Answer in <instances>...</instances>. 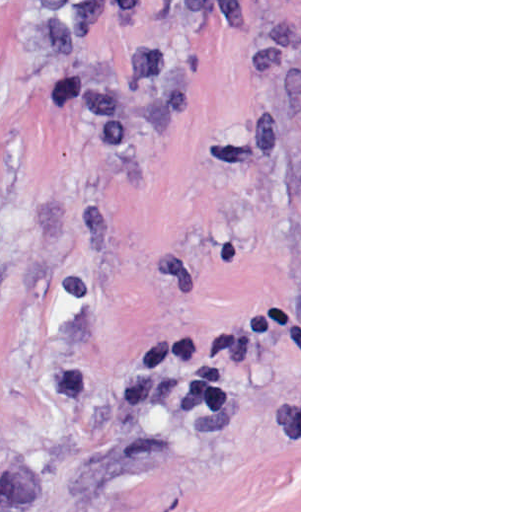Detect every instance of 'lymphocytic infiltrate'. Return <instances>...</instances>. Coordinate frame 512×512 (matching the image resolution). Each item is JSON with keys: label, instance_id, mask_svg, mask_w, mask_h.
<instances>
[{"label": "lymphocytic infiltrate", "instance_id": "obj_1", "mask_svg": "<svg viewBox=\"0 0 512 512\" xmlns=\"http://www.w3.org/2000/svg\"><path fill=\"white\" fill-rule=\"evenodd\" d=\"M110 0H40L33 54L39 67H75L83 38L108 13Z\"/></svg>", "mask_w": 512, "mask_h": 512}]
</instances>
